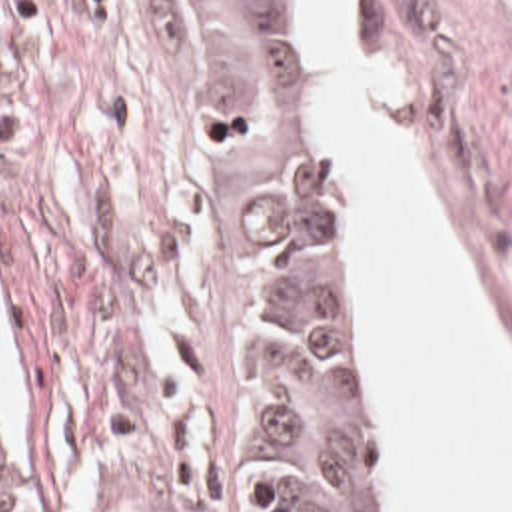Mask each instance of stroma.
Here are the masks:
<instances>
[{"instance_id": "35a3bbf8", "label": "stroma", "mask_w": 512, "mask_h": 512, "mask_svg": "<svg viewBox=\"0 0 512 512\" xmlns=\"http://www.w3.org/2000/svg\"><path fill=\"white\" fill-rule=\"evenodd\" d=\"M303 30L311 18L303 0ZM355 62L399 74L391 128L512 372V0H363ZM317 106V62L313 52ZM353 270L381 512L393 449ZM0 312L25 512H239L257 479V346L227 152L155 0H0Z\"/></svg>"}]
</instances>
